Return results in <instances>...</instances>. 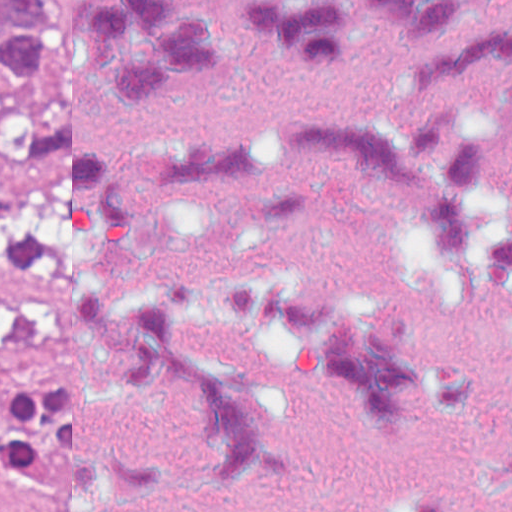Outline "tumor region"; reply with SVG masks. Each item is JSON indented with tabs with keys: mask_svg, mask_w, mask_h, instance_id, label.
<instances>
[{
	"mask_svg": "<svg viewBox=\"0 0 512 512\" xmlns=\"http://www.w3.org/2000/svg\"><path fill=\"white\" fill-rule=\"evenodd\" d=\"M50 65L42 0H0V114L5 104L44 89ZM0 463L29 493H75L64 387L32 383L2 404Z\"/></svg>",
	"mask_w": 512,
	"mask_h": 512,
	"instance_id": "obj_1",
	"label": "tumor region"
}]
</instances>
